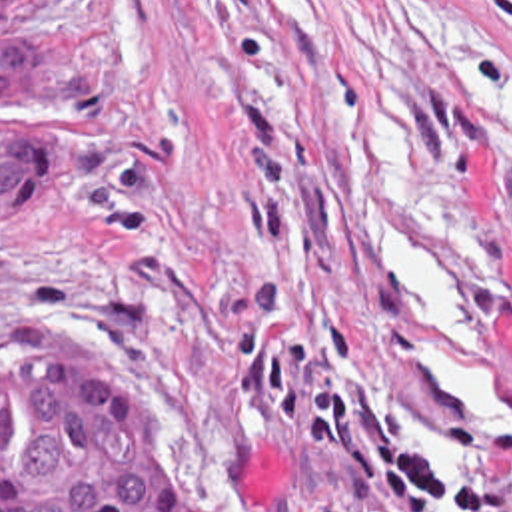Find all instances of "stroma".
<instances>
[{"label":"stroma","instance_id":"stroma-1","mask_svg":"<svg viewBox=\"0 0 512 512\" xmlns=\"http://www.w3.org/2000/svg\"><path fill=\"white\" fill-rule=\"evenodd\" d=\"M512 60V0H421ZM0 42H80L114 58L84 120L90 178L54 218H0V382L126 362L152 392L172 474L202 512H347L335 466L293 450L237 396L245 286L273 276L267 336L357 342L335 374L433 472L501 486L503 462L433 444L451 378L415 304L413 252L365 164V116L421 136L481 222L512 368V160L437 78L399 0H54ZM419 512H465L421 508Z\"/></svg>","mask_w":512,"mask_h":512}]
</instances>
